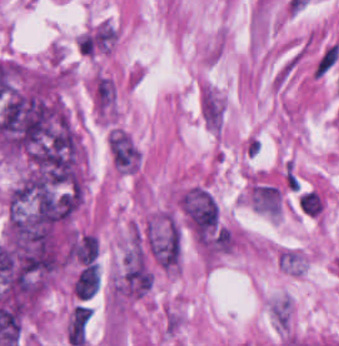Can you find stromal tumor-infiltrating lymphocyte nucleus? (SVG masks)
<instances>
[{"mask_svg":"<svg viewBox=\"0 0 339 346\" xmlns=\"http://www.w3.org/2000/svg\"><path fill=\"white\" fill-rule=\"evenodd\" d=\"M101 283V272L95 261L85 266L76 276L72 287L77 299H91Z\"/></svg>","mask_w":339,"mask_h":346,"instance_id":"1","label":"stromal tumor-infiltrating lymphocyte nucleus"},{"mask_svg":"<svg viewBox=\"0 0 339 346\" xmlns=\"http://www.w3.org/2000/svg\"><path fill=\"white\" fill-rule=\"evenodd\" d=\"M91 314V308L79 304L74 308L67 322V335L71 345H84Z\"/></svg>","mask_w":339,"mask_h":346,"instance_id":"2","label":"stromal tumor-infiltrating lymphocyte nucleus"},{"mask_svg":"<svg viewBox=\"0 0 339 346\" xmlns=\"http://www.w3.org/2000/svg\"><path fill=\"white\" fill-rule=\"evenodd\" d=\"M298 204L300 209L311 217H317L320 215L324 201L320 195L315 190L312 189H304L301 190Z\"/></svg>","mask_w":339,"mask_h":346,"instance_id":"3","label":"stromal tumor-infiltrating lymphocyte nucleus"}]
</instances>
